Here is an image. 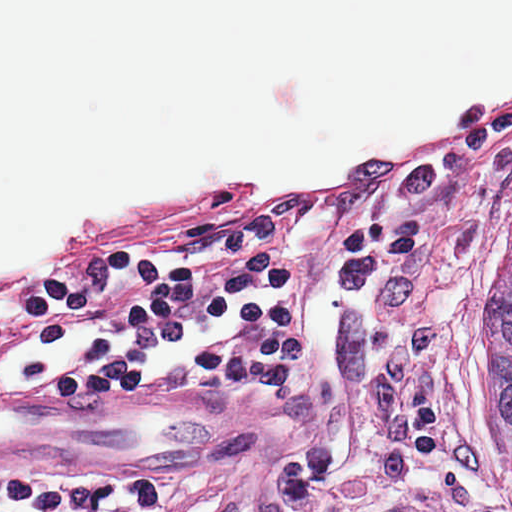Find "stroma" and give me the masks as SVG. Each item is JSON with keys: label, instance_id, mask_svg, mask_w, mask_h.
<instances>
[{"label": "stroma", "instance_id": "35a3bbf8", "mask_svg": "<svg viewBox=\"0 0 512 512\" xmlns=\"http://www.w3.org/2000/svg\"><path fill=\"white\" fill-rule=\"evenodd\" d=\"M142 1V0H140ZM225 188L62 222L0 256V279L38 269L72 236L103 226L223 228ZM153 312L148 280L35 341L0 346V399L66 395L50 372L130 342ZM228 408L223 459L192 466L36 467L0 459L1 512H370L268 285L230 307L213 339L180 353L141 391Z\"/></svg>", "mask_w": 512, "mask_h": 512}]
</instances>
